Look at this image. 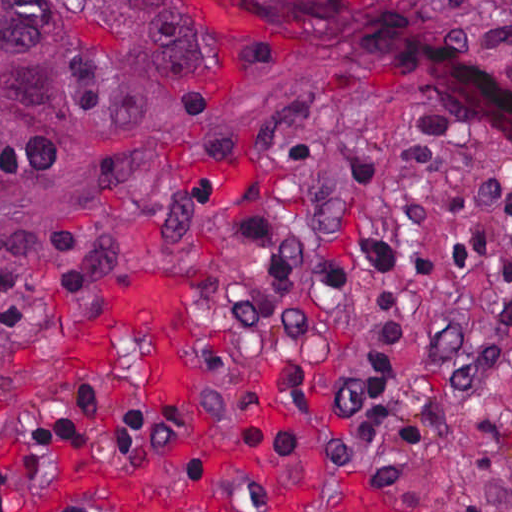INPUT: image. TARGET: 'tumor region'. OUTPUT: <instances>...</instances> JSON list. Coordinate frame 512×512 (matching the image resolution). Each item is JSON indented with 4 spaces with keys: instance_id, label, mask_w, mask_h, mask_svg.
Listing matches in <instances>:
<instances>
[{
    "instance_id": "e687c5a6",
    "label": "tumor region",
    "mask_w": 512,
    "mask_h": 512,
    "mask_svg": "<svg viewBox=\"0 0 512 512\" xmlns=\"http://www.w3.org/2000/svg\"><path fill=\"white\" fill-rule=\"evenodd\" d=\"M274 3L0 0V193L62 139L237 95L315 34ZM405 3L512 84V0Z\"/></svg>"
}]
</instances>
